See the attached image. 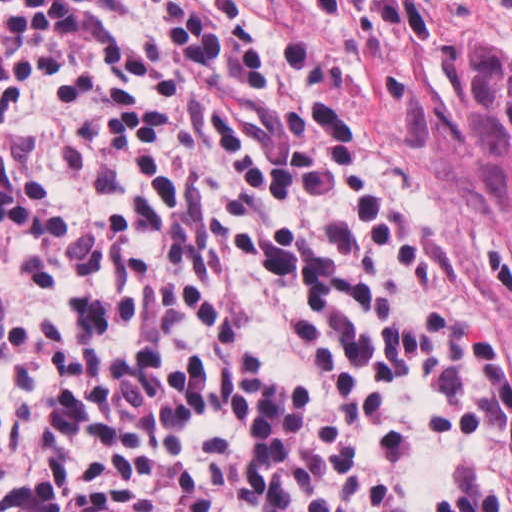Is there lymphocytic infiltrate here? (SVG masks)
Here are the masks:
<instances>
[{"label": "lymphocytic infiltrate", "instance_id": "lymphocytic-infiltrate-1", "mask_svg": "<svg viewBox=\"0 0 512 512\" xmlns=\"http://www.w3.org/2000/svg\"><path fill=\"white\" fill-rule=\"evenodd\" d=\"M0 512H512V332L310 0H0Z\"/></svg>", "mask_w": 512, "mask_h": 512}]
</instances>
